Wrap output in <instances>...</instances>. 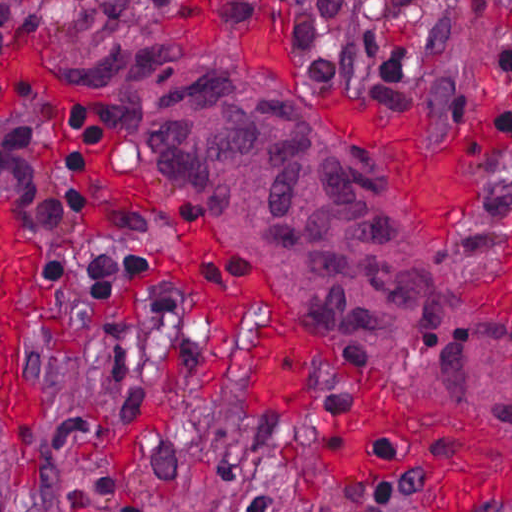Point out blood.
Listing matches in <instances>:
<instances>
[{"instance_id":"1","label":"blood","mask_w":512,"mask_h":512,"mask_svg":"<svg viewBox=\"0 0 512 512\" xmlns=\"http://www.w3.org/2000/svg\"><path fill=\"white\" fill-rule=\"evenodd\" d=\"M333 126L399 159L426 200L439 235L456 241L476 215V137L442 128L417 108L343 96ZM467 225V226H466ZM39 254L23 230L18 204L0 193V417L14 445L15 426L38 416L45 389L23 372L25 330L51 301L15 302ZM353 461L379 475L412 472L427 481L445 512H498L510 499L506 443L443 408L394 390L361 394L346 411Z\"/></svg>"}]
</instances>
